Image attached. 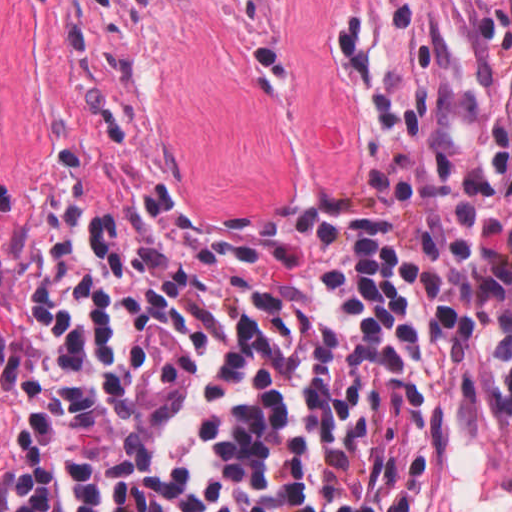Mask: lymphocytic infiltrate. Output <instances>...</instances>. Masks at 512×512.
Segmentation results:
<instances>
[{
  "instance_id": "f902f5d3",
  "label": "lymphocytic infiltrate",
  "mask_w": 512,
  "mask_h": 512,
  "mask_svg": "<svg viewBox=\"0 0 512 512\" xmlns=\"http://www.w3.org/2000/svg\"><path fill=\"white\" fill-rule=\"evenodd\" d=\"M372 211L232 213L57 166L26 265L0 512H439L459 342L512 249L382 150Z\"/></svg>"
}]
</instances>
